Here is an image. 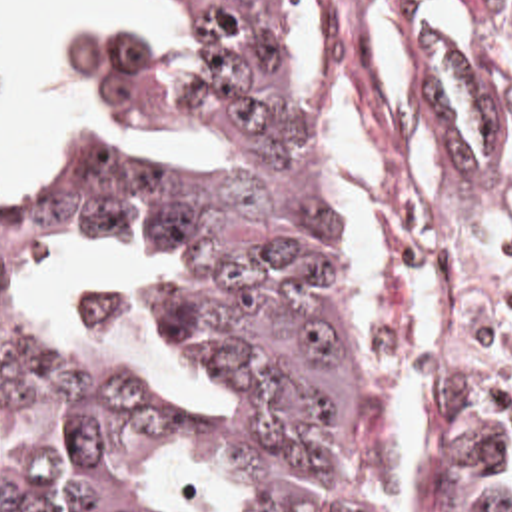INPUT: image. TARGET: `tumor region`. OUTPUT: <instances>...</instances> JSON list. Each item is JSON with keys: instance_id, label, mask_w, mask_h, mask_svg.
<instances>
[{"instance_id": "obj_1", "label": "tumor region", "mask_w": 512, "mask_h": 512, "mask_svg": "<svg viewBox=\"0 0 512 512\" xmlns=\"http://www.w3.org/2000/svg\"><path fill=\"white\" fill-rule=\"evenodd\" d=\"M178 4L190 34L170 56L122 30H84L72 54L142 134L208 140L206 170L40 146L0 196V512H128L168 432V398L20 320L6 286L62 224L188 256L178 284L96 286L72 314L140 330L210 384L258 512H410L420 410L390 416L326 196L302 188L284 0ZM424 86L446 144L500 176L498 102L472 142L428 48ZM420 512H512V412L466 396L446 412Z\"/></svg>"}]
</instances>
